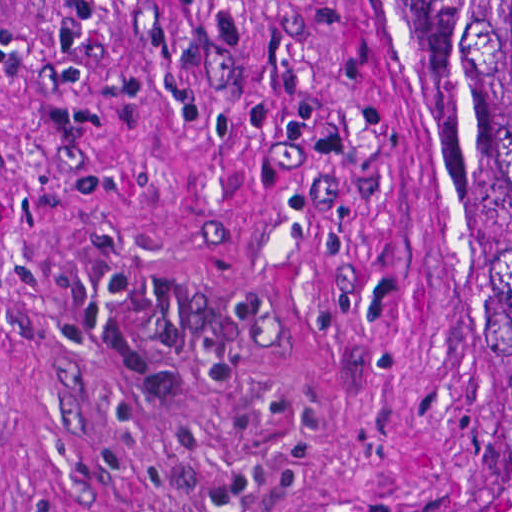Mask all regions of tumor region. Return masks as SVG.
I'll return each instance as SVG.
<instances>
[{
    "label": "tumor region",
    "mask_w": 512,
    "mask_h": 512,
    "mask_svg": "<svg viewBox=\"0 0 512 512\" xmlns=\"http://www.w3.org/2000/svg\"><path fill=\"white\" fill-rule=\"evenodd\" d=\"M426 51V463L512 512V0H415Z\"/></svg>",
    "instance_id": "e687c5a6"
}]
</instances>
